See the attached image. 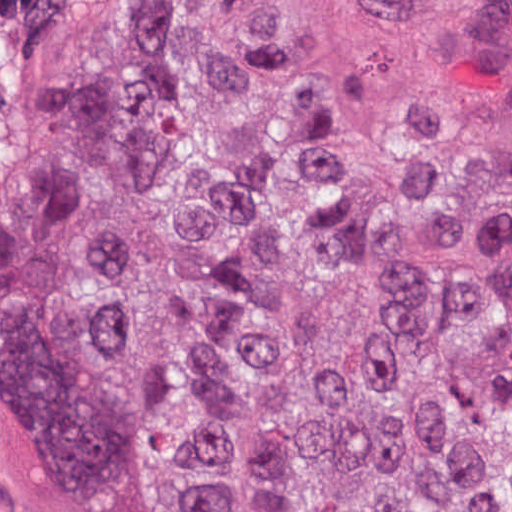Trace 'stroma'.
Returning <instances> with one entry per match:
<instances>
[{"mask_svg": "<svg viewBox=\"0 0 512 512\" xmlns=\"http://www.w3.org/2000/svg\"><path fill=\"white\" fill-rule=\"evenodd\" d=\"M0 512H73L50 462L1 386Z\"/></svg>", "mask_w": 512, "mask_h": 512, "instance_id": "stroma-1", "label": "stroma"}]
</instances>
